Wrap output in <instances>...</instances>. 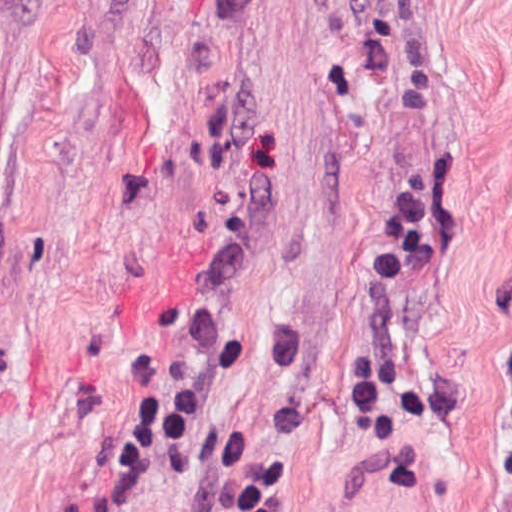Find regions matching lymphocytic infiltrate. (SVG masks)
Segmentation results:
<instances>
[{
  "label": "lymphocytic infiltrate",
  "instance_id": "obj_1",
  "mask_svg": "<svg viewBox=\"0 0 512 512\" xmlns=\"http://www.w3.org/2000/svg\"><path fill=\"white\" fill-rule=\"evenodd\" d=\"M403 189L378 235L336 378V445L369 436L387 408L407 315L442 235L446 201L421 187L387 197ZM156 366L106 439L69 512H133L143 500L188 485L209 492L211 512H293L292 481L276 465L207 435L192 398L153 374Z\"/></svg>",
  "mask_w": 512,
  "mask_h": 512
}]
</instances>
